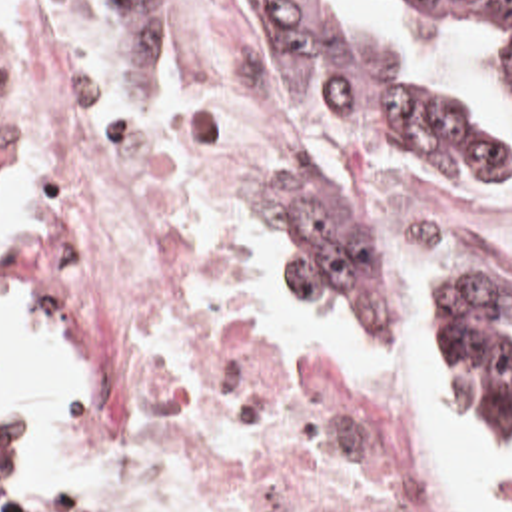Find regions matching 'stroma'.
<instances>
[{
    "mask_svg": "<svg viewBox=\"0 0 512 512\" xmlns=\"http://www.w3.org/2000/svg\"><path fill=\"white\" fill-rule=\"evenodd\" d=\"M211 11L251 23L289 75V113L283 141L263 183H301L325 209L355 219L357 223L347 229L375 245V321H341L319 297L309 295L331 317L339 332L355 340L409 342L422 354L421 338L407 313L409 305H401L399 299L393 235L377 211L337 197L305 171L311 139L379 155L422 185L478 201H512V171H444L375 131L353 129L337 121L319 105L305 85L285 35L257 0H151L143 3L7 0V25L0 29V49H21L45 43L151 41L183 35L179 33L181 29ZM0 195L11 209V235L0 253V305L33 311L65 326L77 346L79 384L65 396L57 416L67 436L83 444L105 446L115 456L139 464L147 488L179 512H257L239 508L207 492L161 456L127 444L95 418L103 388V338L89 309L59 295L33 267L39 239V197L13 191H3ZM265 249H269V243L263 219L259 217L243 269V309L247 325L251 265ZM440 279L512 281V269L490 249H484L456 255ZM251 342L257 376L271 406L307 422L365 466L403 480L428 512H444L432 496L415 456L385 438L339 384L319 378L307 360L291 352L269 348L253 336ZM452 410L470 424H512V346L502 350L484 412ZM0 512L89 510L77 506H3L0 502Z\"/></svg>",
    "mask_w": 512,
    "mask_h": 512,
    "instance_id": "stroma-1",
    "label": "stroma"
}]
</instances>
